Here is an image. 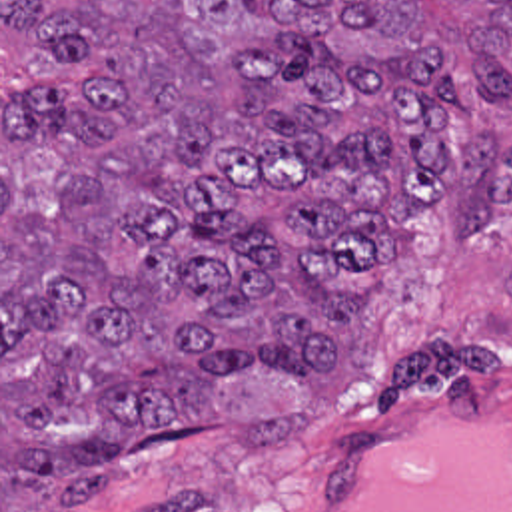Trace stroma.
I'll return each mask as SVG.
<instances>
[{"instance_id": "obj_1", "label": "stroma", "mask_w": 512, "mask_h": 512, "mask_svg": "<svg viewBox=\"0 0 512 512\" xmlns=\"http://www.w3.org/2000/svg\"><path fill=\"white\" fill-rule=\"evenodd\" d=\"M469 105L497 139H512V99L495 101L481 85ZM361 319V356L323 372L303 420L256 444L174 442L126 464L112 494L74 510L0 492V512H319L341 460L379 432L457 412L512 418V205L487 241L421 215Z\"/></svg>"}]
</instances>
